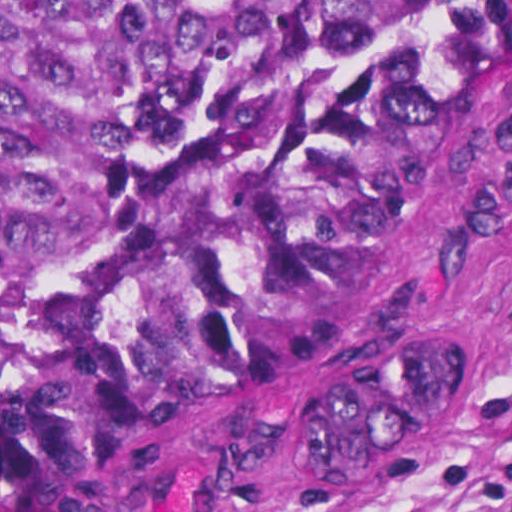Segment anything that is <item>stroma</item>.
I'll return each mask as SVG.
<instances>
[{
	"mask_svg": "<svg viewBox=\"0 0 512 512\" xmlns=\"http://www.w3.org/2000/svg\"><path fill=\"white\" fill-rule=\"evenodd\" d=\"M432 322L466 342L467 367L400 468L362 483L304 470L305 384ZM511 379L512 57L438 120L312 350L65 493L0 494V512H512V424L482 415ZM5 381L1 366V397Z\"/></svg>",
	"mask_w": 512,
	"mask_h": 512,
	"instance_id": "obj_1",
	"label": "stroma"
}]
</instances>
